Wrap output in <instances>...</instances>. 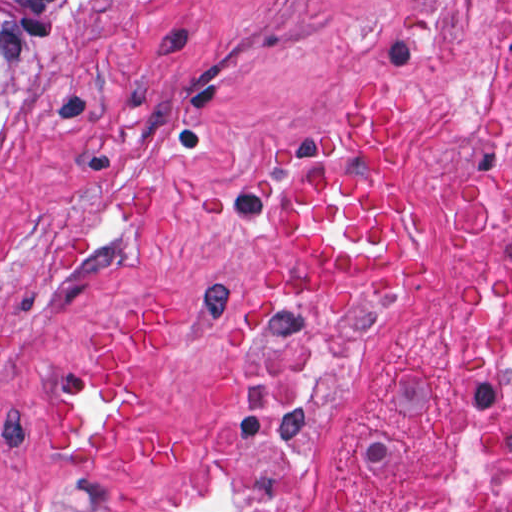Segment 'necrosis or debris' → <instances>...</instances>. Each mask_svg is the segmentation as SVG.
<instances>
[{
    "label": "necrosis or debris",
    "mask_w": 512,
    "mask_h": 512,
    "mask_svg": "<svg viewBox=\"0 0 512 512\" xmlns=\"http://www.w3.org/2000/svg\"><path fill=\"white\" fill-rule=\"evenodd\" d=\"M358 318L284 301L251 321L224 379L231 438L187 512H274L311 430L349 377ZM446 466L434 483L356 512H512V75L461 188L443 289Z\"/></svg>",
    "instance_id": "necrosis-or-debris-1"
}]
</instances>
